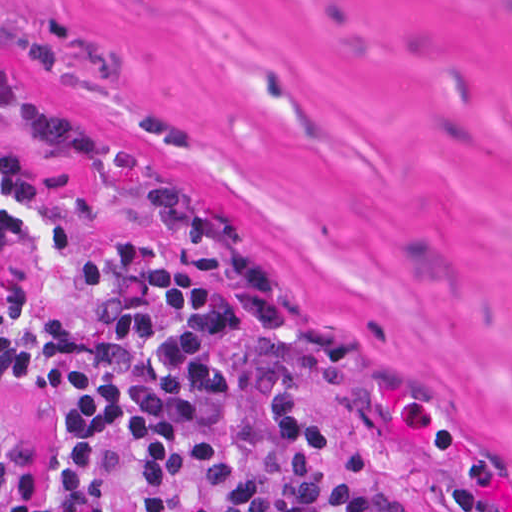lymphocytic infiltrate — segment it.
I'll list each match as a JSON object with an SVG mask.
<instances>
[{"mask_svg": "<svg viewBox=\"0 0 512 512\" xmlns=\"http://www.w3.org/2000/svg\"><path fill=\"white\" fill-rule=\"evenodd\" d=\"M0 371L58 391L45 492L0 417V512H429L75 135L1 107Z\"/></svg>", "mask_w": 512, "mask_h": 512, "instance_id": "lymphocytic-infiltrate-1", "label": "lymphocytic infiltrate"}]
</instances>
